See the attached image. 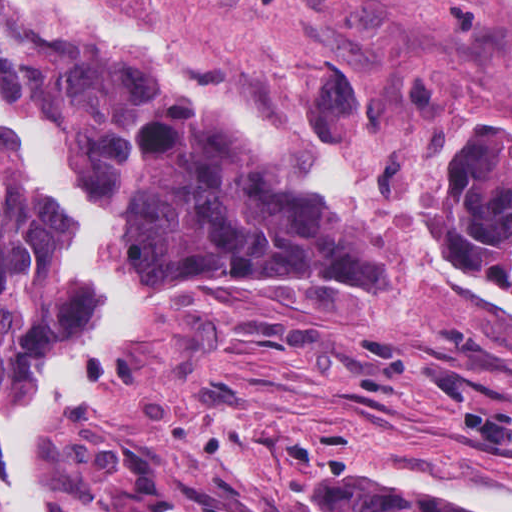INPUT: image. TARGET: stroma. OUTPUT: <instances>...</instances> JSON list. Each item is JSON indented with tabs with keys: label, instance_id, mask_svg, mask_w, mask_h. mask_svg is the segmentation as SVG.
Instances as JSON below:
<instances>
[{
	"label": "stroma",
	"instance_id": "obj_1",
	"mask_svg": "<svg viewBox=\"0 0 512 512\" xmlns=\"http://www.w3.org/2000/svg\"><path fill=\"white\" fill-rule=\"evenodd\" d=\"M75 1L178 36L217 85L325 141L357 212L201 100L384 286L240 280L185 298L38 442L43 510L109 512L97 454L157 461L186 499L236 512H310L323 479L356 467L365 501L372 468L512 489V283L459 245L438 179L467 128L512 116V0Z\"/></svg>",
	"mask_w": 512,
	"mask_h": 512
}]
</instances>
